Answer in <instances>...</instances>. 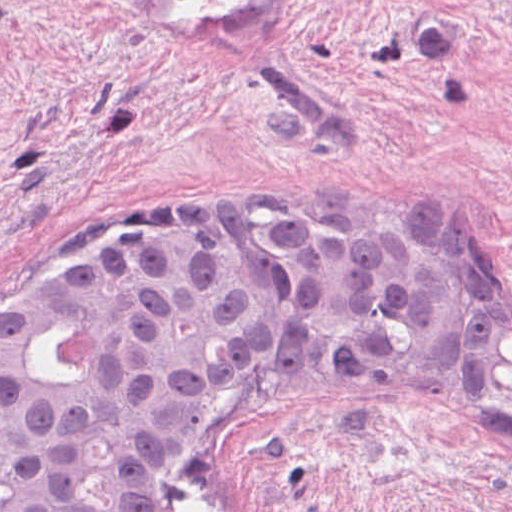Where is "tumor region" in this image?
I'll return each instance as SVG.
<instances>
[{"mask_svg": "<svg viewBox=\"0 0 512 512\" xmlns=\"http://www.w3.org/2000/svg\"><path fill=\"white\" fill-rule=\"evenodd\" d=\"M285 402L454 429L512 461V284L359 208L212 212L0 318V512H178L212 440Z\"/></svg>", "mask_w": 512, "mask_h": 512, "instance_id": "obj_1", "label": "tumor region"}]
</instances>
